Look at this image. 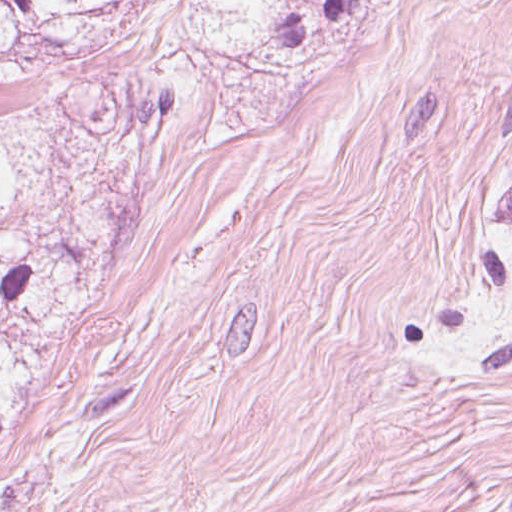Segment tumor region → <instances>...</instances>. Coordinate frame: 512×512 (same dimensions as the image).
I'll list each match as a JSON object with an SVG mask.
<instances>
[{
    "label": "tumor region",
    "mask_w": 512,
    "mask_h": 512,
    "mask_svg": "<svg viewBox=\"0 0 512 512\" xmlns=\"http://www.w3.org/2000/svg\"><path fill=\"white\" fill-rule=\"evenodd\" d=\"M512 361V304L503 320L499 336L493 342L485 372L499 369Z\"/></svg>",
    "instance_id": "obj_1"
}]
</instances>
